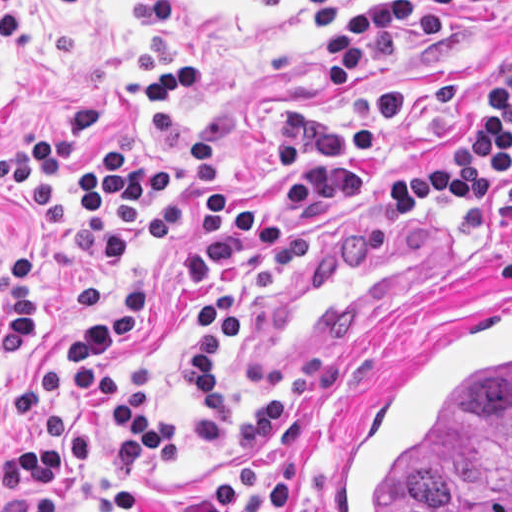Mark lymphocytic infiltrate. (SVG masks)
Instances as JSON below:
<instances>
[{
  "instance_id": "f902f5d3",
  "label": "lymphocytic infiltrate",
  "mask_w": 512,
  "mask_h": 512,
  "mask_svg": "<svg viewBox=\"0 0 512 512\" xmlns=\"http://www.w3.org/2000/svg\"><path fill=\"white\" fill-rule=\"evenodd\" d=\"M346 0H311L320 33ZM485 0H389L359 11L324 39V86L344 93L373 60L424 52L448 17ZM289 0H273L283 12ZM132 65L145 81L129 82L85 97L51 117L23 143L0 154V210L13 223L10 256L0 276V355L23 359L38 339V282L28 259L18 214L34 210L48 232L63 226V202L55 187L70 157L99 119L125 96L142 97L152 109L199 87L201 58L179 54L169 34L142 41ZM405 127L401 88L374 92L350 117L318 101L291 105L276 122V146L269 166L285 182V194L251 211L224 185L217 149L194 132L188 165L195 177L197 236L177 284L197 321V334L181 349L183 386L195 404L188 428L195 437L221 440L229 432L222 398V349L231 343L244 316L243 290L267 293L278 287L305 252L298 224L287 204L311 199L328 212L360 191L365 177L353 157L379 149ZM173 166H147L128 136L109 140L93 162L68 173L70 211L75 224L102 238L111 261L125 259L134 243L114 223L119 212H137L175 194ZM431 196L445 200L465 222H483L491 199L512 216V68L485 76L461 114L457 141L428 144L418 172L379 185L382 214L424 206ZM512 281V251L499 261ZM156 307V291L135 279L118 285L101 312L59 327L70 349L75 391L109 417L138 449L160 459L173 457V434L162 418L141 405L114 373L115 344ZM342 382V363H318L303 371L285 408L276 388L267 391L241 433L243 446L227 474L198 497L170 503L145 496L136 483L122 488L123 512H285L299 483V463L276 458L300 433L313 405ZM65 383L56 370L36 373L17 386L16 406L26 422L19 448L0 463L4 499L0 512H69L70 488L97 462L102 432L75 425L59 412Z\"/></svg>"
}]
</instances>
